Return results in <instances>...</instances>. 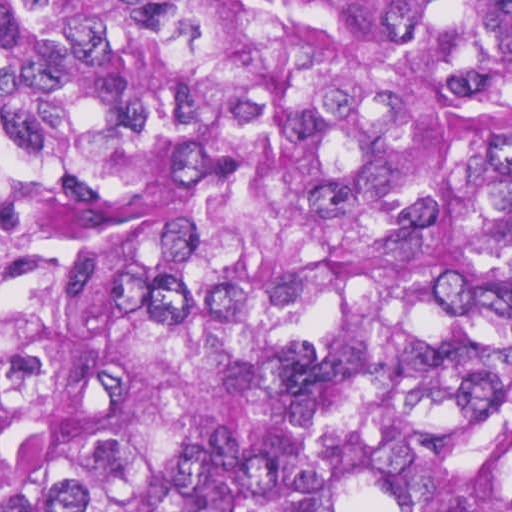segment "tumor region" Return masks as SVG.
Returning a JSON list of instances; mask_svg holds the SVG:
<instances>
[{
  "label": "tumor region",
  "instance_id": "e687c5a6",
  "mask_svg": "<svg viewBox=\"0 0 512 512\" xmlns=\"http://www.w3.org/2000/svg\"><path fill=\"white\" fill-rule=\"evenodd\" d=\"M0 512H512V0H0Z\"/></svg>",
  "mask_w": 512,
  "mask_h": 512
}]
</instances>
